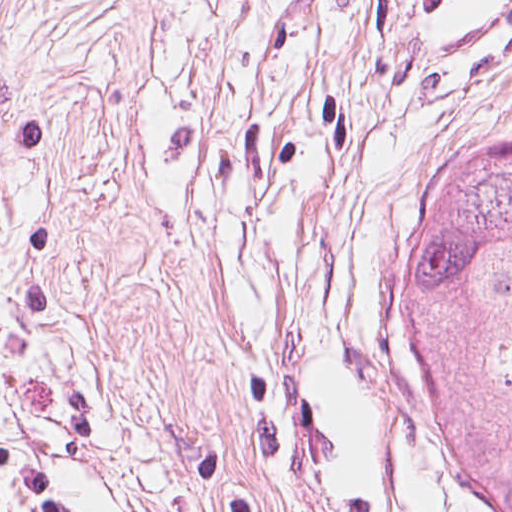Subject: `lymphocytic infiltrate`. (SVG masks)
<instances>
[{
	"label": "lymphocytic infiltrate",
	"mask_w": 512,
	"mask_h": 512,
	"mask_svg": "<svg viewBox=\"0 0 512 512\" xmlns=\"http://www.w3.org/2000/svg\"><path fill=\"white\" fill-rule=\"evenodd\" d=\"M0 512H81L72 496L33 457L0 445Z\"/></svg>",
	"instance_id": "obj_1"
}]
</instances>
